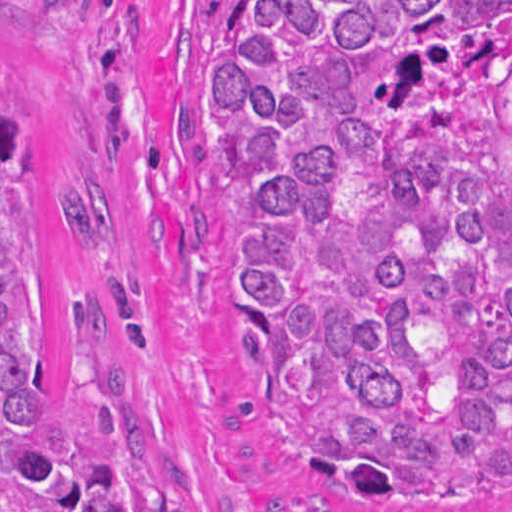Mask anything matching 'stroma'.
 <instances>
[{"label":"stroma","mask_w":512,"mask_h":512,"mask_svg":"<svg viewBox=\"0 0 512 512\" xmlns=\"http://www.w3.org/2000/svg\"><path fill=\"white\" fill-rule=\"evenodd\" d=\"M210 1L512 0H0V58L37 117V394L67 388L73 311L94 293L191 512H512L357 508L265 432L230 351L243 219L209 102Z\"/></svg>","instance_id":"35a3bbf8"}]
</instances>
